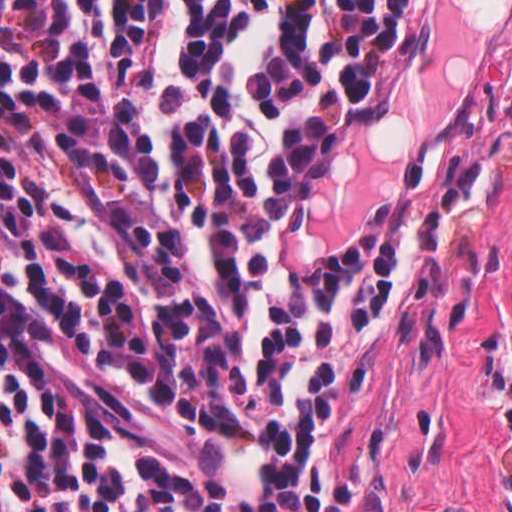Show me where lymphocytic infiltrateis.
I'll use <instances>...</instances> for the list:
<instances>
[{
	"label": "lymphocytic infiltrate",
	"mask_w": 512,
	"mask_h": 512,
	"mask_svg": "<svg viewBox=\"0 0 512 512\" xmlns=\"http://www.w3.org/2000/svg\"><path fill=\"white\" fill-rule=\"evenodd\" d=\"M439 55V0H0V512H339L371 330L486 202L416 156L363 245L315 200Z\"/></svg>",
	"instance_id": "f902f5d3"
}]
</instances>
